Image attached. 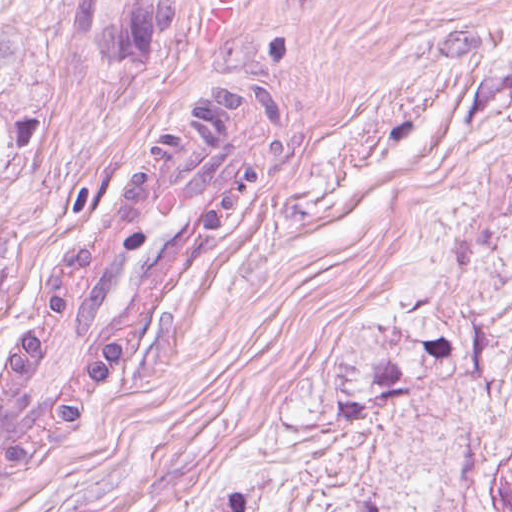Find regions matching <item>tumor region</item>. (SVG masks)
<instances>
[{
  "label": "tumor region",
  "mask_w": 512,
  "mask_h": 512,
  "mask_svg": "<svg viewBox=\"0 0 512 512\" xmlns=\"http://www.w3.org/2000/svg\"><path fill=\"white\" fill-rule=\"evenodd\" d=\"M458 342L409 336L350 374L328 370L286 428L343 427L421 393ZM459 471L446 512H512V283L483 337L452 418ZM246 491L217 512H240Z\"/></svg>",
  "instance_id": "tumor-region-1"
}]
</instances>
